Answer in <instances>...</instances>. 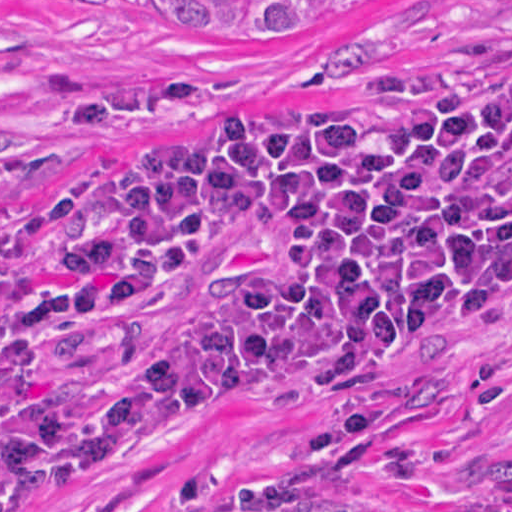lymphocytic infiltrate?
Segmentation results:
<instances>
[{"label":"lymphocytic infiltrate","mask_w":512,"mask_h":512,"mask_svg":"<svg viewBox=\"0 0 512 512\" xmlns=\"http://www.w3.org/2000/svg\"><path fill=\"white\" fill-rule=\"evenodd\" d=\"M511 67L512 66L507 67V68H511ZM500 76H507L506 72L503 69L499 70V71H497V72H495V73H493V74H491L489 76H485V77L479 79L478 81H476L474 83L481 82V81H486V80H490V79H494V78H497V77H500ZM356 105H361V104H334V105L323 106V107H321L319 109H316L314 111L330 110V109L344 108V107H350V106H356ZM196 106H204V105L196 104ZM249 121H269V120H249ZM3 172H4V169L0 166V187H1V182H2ZM114 189H112L110 191V193L107 195V197L104 199V201L102 202V204L99 207L98 211L109 201V199H110ZM13 216L17 219V221H18V223L20 225V228H21V230L23 232V242H25L37 229L31 224V222L26 217L15 216V215H13ZM278 276H279V272L275 273L274 275H272L269 278L265 279L264 281L260 282L258 285L254 286L252 288H249L247 290H244V291L238 293L237 295H235L234 297L229 298L225 302L219 304L218 306L212 308L209 311H213V310L222 308V307H224V306H226V305H228V304H230V303H232V302H234V301H236V300H238V299H240L242 297H246V296H248L250 294H253V293L259 291L260 289H262V288L268 286L269 284L273 283L274 281L278 280ZM209 311H207V312H209ZM62 403L63 402L58 403L55 406H53L51 408H48L47 410L43 411L42 413H44V412H46V411H48V410H50L52 408H55V407H57L58 405H60ZM42 413H40V414H42Z\"/></svg>","instance_id":"lymphocytic-infiltrate-1"}]
</instances>
